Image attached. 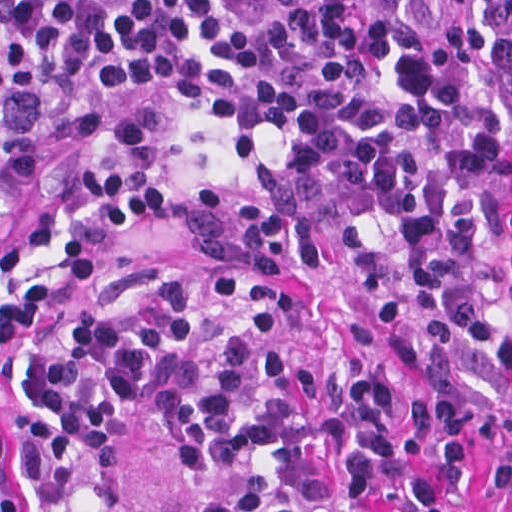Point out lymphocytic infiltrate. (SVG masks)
<instances>
[{
    "label": "lymphocytic infiltrate",
    "instance_id": "1",
    "mask_svg": "<svg viewBox=\"0 0 512 512\" xmlns=\"http://www.w3.org/2000/svg\"><path fill=\"white\" fill-rule=\"evenodd\" d=\"M98 97H201L306 137L187 198L219 267L341 289L430 385L218 319L161 279L32 332L1 512H512V0H1V174Z\"/></svg>",
    "mask_w": 512,
    "mask_h": 512
}]
</instances>
